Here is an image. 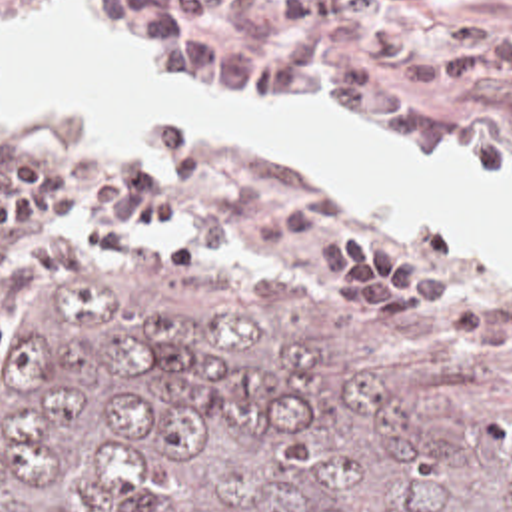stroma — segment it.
Masks as SVG:
<instances>
[{"label":"stroma","instance_id":"35a3bbf8","mask_svg":"<svg viewBox=\"0 0 512 512\" xmlns=\"http://www.w3.org/2000/svg\"><path fill=\"white\" fill-rule=\"evenodd\" d=\"M48 1L52 0H0V7H32ZM367 13L375 17L403 19L415 25L419 37L427 43L477 17H495L512 27V0H441V11L431 15L403 13L385 5H371ZM85 19L93 33L111 47L131 55L145 71L167 81L197 87L187 79L155 67L143 55L137 41L103 33L89 11L85 13ZM423 99L427 105H445L467 111L483 121L491 135V152L485 158H413L373 141L351 121L307 117L265 103L255 105L283 113L301 125L325 127L385 158L437 170L512 172V85L489 95H423ZM173 121L183 123L195 142L209 146L215 154L213 182L193 198L191 212H229L251 206L261 196L281 188L297 176L267 156L233 154L221 148L211 131L193 119ZM153 125L145 127L141 135L99 152L60 148L40 135L0 127V178H4V168L20 158H46L66 170L75 198L91 184L101 164L151 148ZM315 186L325 194V224L307 238L291 242L267 256L235 262L201 254L181 220H171L173 226L145 234L137 248L121 254L101 252L75 238L77 260L70 272H46L12 286H0V308L58 278L83 272H129L141 264L169 260L211 268L247 286L319 306L359 328L373 346L397 356L411 372L425 380H512L511 284L465 252L455 240L413 226L379 208L347 204L339 196L327 192L321 184L315 182ZM353 226H379L393 238L403 254L419 258L435 268L443 278V298L411 312L405 324H373L363 306L351 302L343 292L341 258L331 246L335 230Z\"/></svg>","mask_w":512,"mask_h":512}]
</instances>
